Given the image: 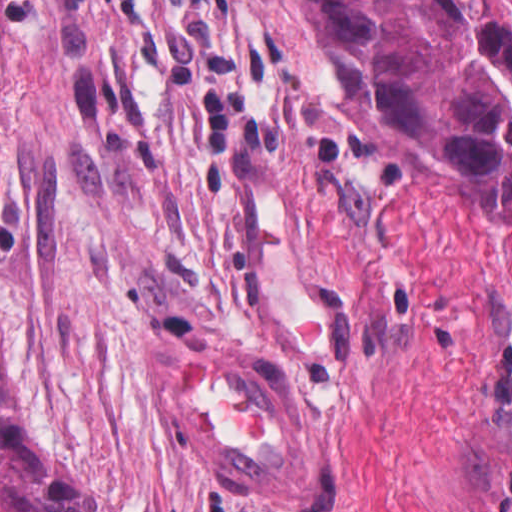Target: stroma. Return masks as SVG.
I'll use <instances>...</instances> for the list:
<instances>
[{
	"label": "stroma",
	"instance_id": "obj_1",
	"mask_svg": "<svg viewBox=\"0 0 512 512\" xmlns=\"http://www.w3.org/2000/svg\"><path fill=\"white\" fill-rule=\"evenodd\" d=\"M271 330L342 417L322 507L214 498L157 416L158 349ZM0 370L97 512H512V224L296 0H7Z\"/></svg>",
	"mask_w": 512,
	"mask_h": 512
}]
</instances>
